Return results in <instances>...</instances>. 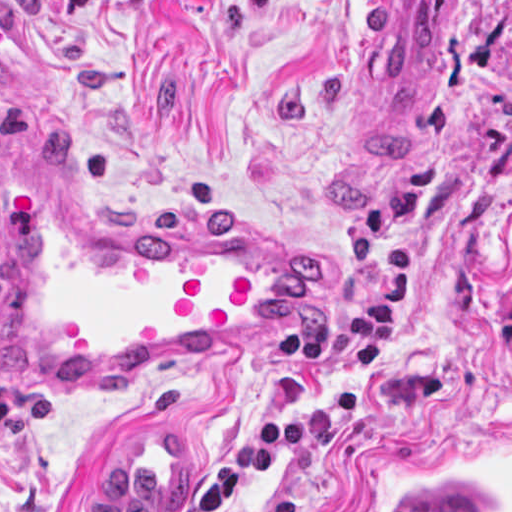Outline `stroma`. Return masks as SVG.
<instances>
[{"label":"stroma","mask_w":512,"mask_h":512,"mask_svg":"<svg viewBox=\"0 0 512 512\" xmlns=\"http://www.w3.org/2000/svg\"><path fill=\"white\" fill-rule=\"evenodd\" d=\"M374 0H0V132L80 191L333 265L304 332L70 397L0 381V506L81 512L129 434L188 438L185 502L276 412L311 445L239 512H512V0H458L415 104L365 65Z\"/></svg>","instance_id":"obj_1"}]
</instances>
